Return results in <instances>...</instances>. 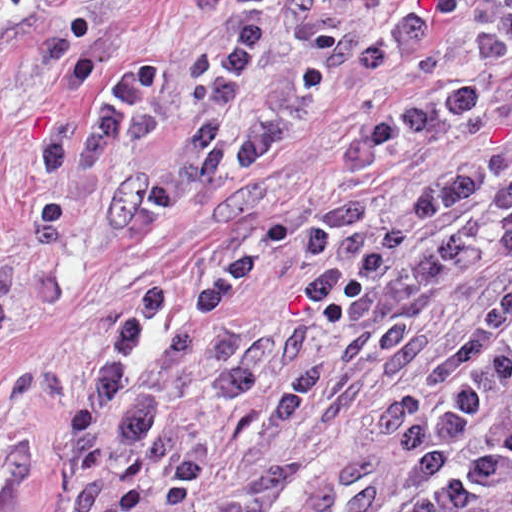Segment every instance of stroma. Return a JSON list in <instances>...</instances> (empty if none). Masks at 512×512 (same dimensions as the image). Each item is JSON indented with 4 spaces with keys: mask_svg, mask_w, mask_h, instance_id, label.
<instances>
[{
    "mask_svg": "<svg viewBox=\"0 0 512 512\" xmlns=\"http://www.w3.org/2000/svg\"><path fill=\"white\" fill-rule=\"evenodd\" d=\"M14 0H0V512H1V36ZM241 0H126L133 33L170 60L203 49L227 32ZM370 115L366 87L342 84L312 127L260 169L223 186L189 219L142 248L109 254L76 276L13 347L9 380H30L14 421L34 452V465L8 512H61L62 477L52 454L62 415V382L82 378L84 346L103 316L195 262L236 231L261 222L285 223L283 244L237 302L236 317L259 331L317 336L286 357L244 406L230 408L210 388L205 351L187 349L162 383L167 416L202 430L206 465L190 501L159 512H207L253 476L312 456L338 461L362 457L386 413L417 388L447 340L512 283V258L498 249L494 216L477 221V255L461 279L425 312L410 346L390 375L353 416L319 435L272 437L273 397L285 377L319 356L341 331L337 319L300 310L296 259L318 214L354 207L367 220L386 213L483 149L512 151V69L502 82L483 129L428 148L392 172L365 177L343 171L337 152Z\"/></svg>",
    "mask_w": 512,
    "mask_h": 512,
    "instance_id": "stroma-1",
    "label": "stroma"
}]
</instances>
